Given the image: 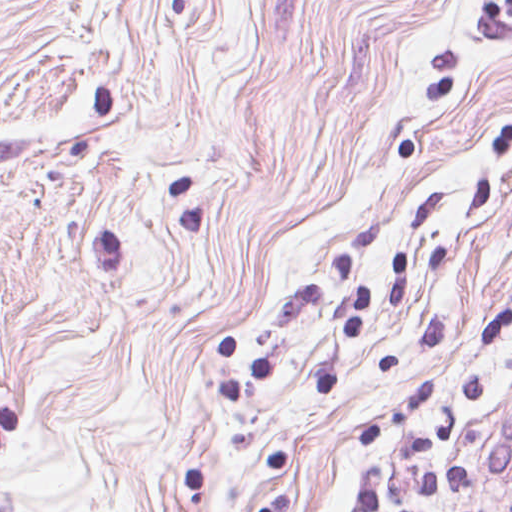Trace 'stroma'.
I'll return each instance as SVG.
<instances>
[{
	"label": "stroma",
	"instance_id": "1",
	"mask_svg": "<svg viewBox=\"0 0 512 512\" xmlns=\"http://www.w3.org/2000/svg\"><path fill=\"white\" fill-rule=\"evenodd\" d=\"M512 512V0H0V512Z\"/></svg>",
	"mask_w": 512,
	"mask_h": 512
}]
</instances>
